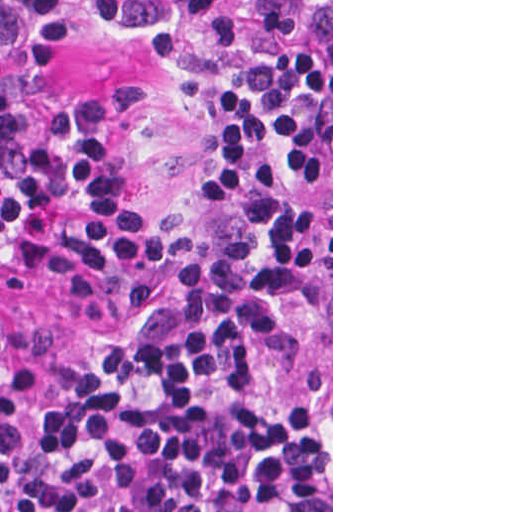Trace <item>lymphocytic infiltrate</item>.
I'll return each mask as SVG.
<instances>
[{"mask_svg": "<svg viewBox=\"0 0 512 512\" xmlns=\"http://www.w3.org/2000/svg\"><path fill=\"white\" fill-rule=\"evenodd\" d=\"M81 34L203 114L181 204L130 184L140 91L61 110ZM7 269L58 278L81 343L0 384V512H331V50L298 0H0Z\"/></svg>", "mask_w": 512, "mask_h": 512, "instance_id": "lymphocytic-infiltrate-1", "label": "lymphocytic infiltrate"}]
</instances>
